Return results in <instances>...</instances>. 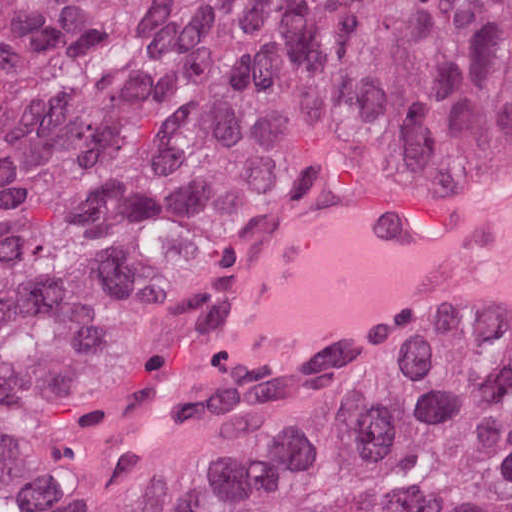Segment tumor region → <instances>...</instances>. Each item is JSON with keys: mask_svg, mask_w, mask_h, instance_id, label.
Listing matches in <instances>:
<instances>
[{"mask_svg": "<svg viewBox=\"0 0 512 512\" xmlns=\"http://www.w3.org/2000/svg\"><path fill=\"white\" fill-rule=\"evenodd\" d=\"M512 188V0H0V512H512V341L251 357L332 204Z\"/></svg>", "mask_w": 512, "mask_h": 512, "instance_id": "1", "label": "tumor region"}]
</instances>
